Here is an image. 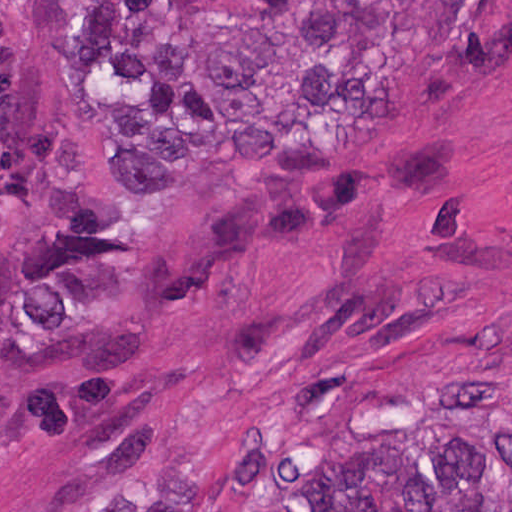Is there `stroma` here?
Instances as JSON below:
<instances>
[{
    "mask_svg": "<svg viewBox=\"0 0 512 512\" xmlns=\"http://www.w3.org/2000/svg\"><path fill=\"white\" fill-rule=\"evenodd\" d=\"M0 0V512H249L326 428L512 390V0L431 103L167 194Z\"/></svg>",
    "mask_w": 512,
    "mask_h": 512,
    "instance_id": "1",
    "label": "stroma"
}]
</instances>
